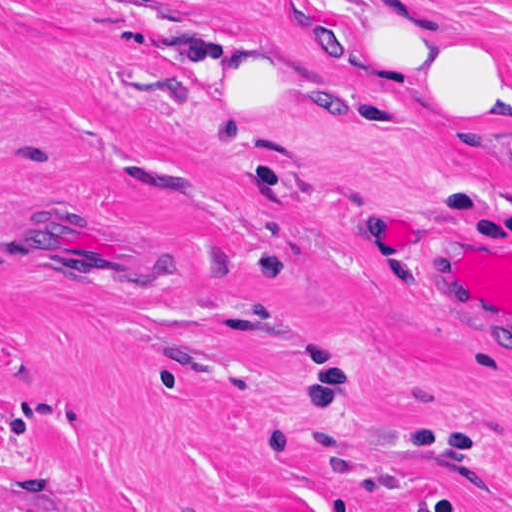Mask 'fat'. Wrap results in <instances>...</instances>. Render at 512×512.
<instances>
[{"label":"fat","instance_id":"obj_1","mask_svg":"<svg viewBox=\"0 0 512 512\" xmlns=\"http://www.w3.org/2000/svg\"><path fill=\"white\" fill-rule=\"evenodd\" d=\"M350 100L405 107L512 157V65L500 33L434 0H366L344 27Z\"/></svg>","mask_w":512,"mask_h":512}]
</instances>
